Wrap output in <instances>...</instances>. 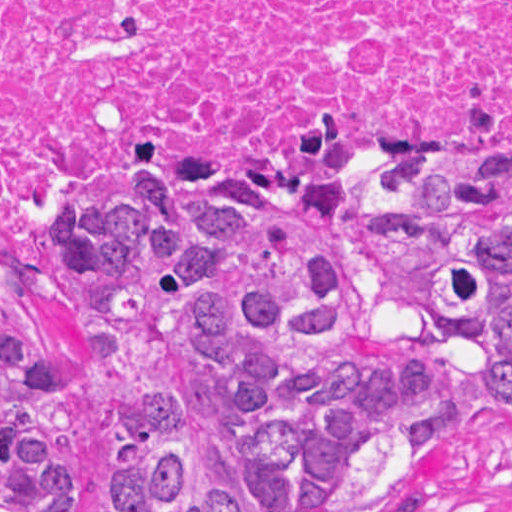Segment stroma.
<instances>
[{
	"label": "stroma",
	"mask_w": 512,
	"mask_h": 512,
	"mask_svg": "<svg viewBox=\"0 0 512 512\" xmlns=\"http://www.w3.org/2000/svg\"><path fill=\"white\" fill-rule=\"evenodd\" d=\"M365 175L340 173L343 254L359 312L378 347L432 350L456 369L467 388V415L424 452L415 475L427 471L429 481V501L420 512H512V423L485 408L490 376L478 351L423 335L412 320L386 304L369 280L353 240ZM55 238V263L29 278H0V312L31 332L40 330L53 354L55 397L75 424L83 460L82 512H99L104 466L96 427V379L69 340V278L56 233Z\"/></svg>",
	"instance_id": "35a3bbf8"
}]
</instances>
